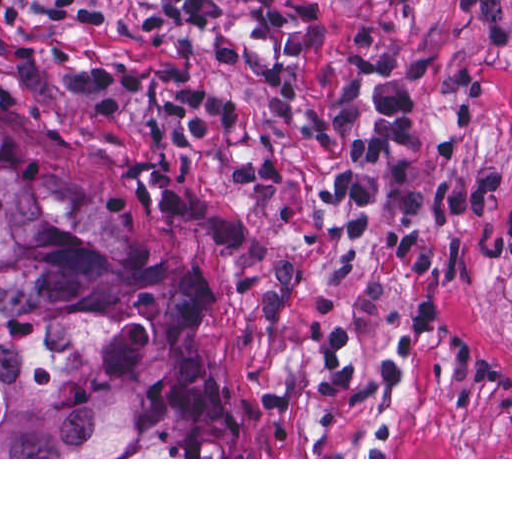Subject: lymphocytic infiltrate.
<instances>
[{"label":"lymphocytic infiltrate","mask_w":512,"mask_h":512,"mask_svg":"<svg viewBox=\"0 0 512 512\" xmlns=\"http://www.w3.org/2000/svg\"><path fill=\"white\" fill-rule=\"evenodd\" d=\"M95 29L216 30L229 41V12L217 0H42ZM508 0H448L450 16L481 33L495 55L511 50ZM443 54L398 49L381 30L362 28L345 47L347 78L338 98L312 120L313 134H339L347 146L341 168L315 191L318 203L339 210L354 238L370 221V207L384 206L381 228L399 302L391 326L398 355L419 357L432 328L438 292L434 280V220L480 216L505 187V171L484 168L447 175L424 190L389 177L390 168L416 162L421 148L420 101L424 80ZM196 67L183 63L89 66L75 78L91 106L116 120L135 100L159 94V113L147 117V134L181 148H219L245 136L257 151L231 168L238 185H283L287 163L280 145L251 105L197 86Z\"/></svg>","instance_id":"1"}]
</instances>
